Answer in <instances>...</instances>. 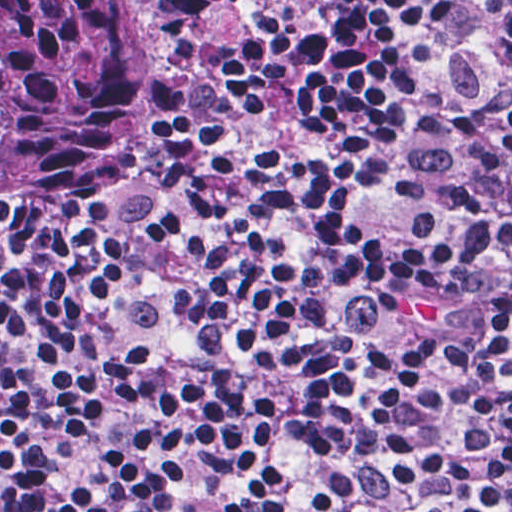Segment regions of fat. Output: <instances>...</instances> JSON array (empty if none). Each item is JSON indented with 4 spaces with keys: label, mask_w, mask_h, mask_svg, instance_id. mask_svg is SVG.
Segmentation results:
<instances>
[{
    "label": "fat",
    "mask_w": 512,
    "mask_h": 512,
    "mask_svg": "<svg viewBox=\"0 0 512 512\" xmlns=\"http://www.w3.org/2000/svg\"><path fill=\"white\" fill-rule=\"evenodd\" d=\"M395 317L424 327H433L446 317V299L442 292L415 290L396 297L390 306Z\"/></svg>",
    "instance_id": "obj_1"
}]
</instances>
